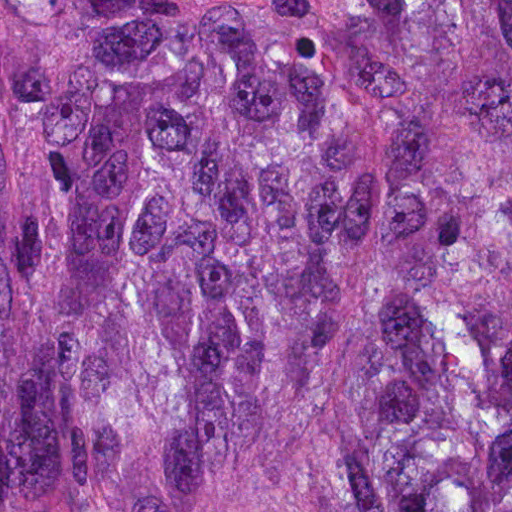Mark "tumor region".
<instances>
[{
    "label": "tumor region",
    "mask_w": 512,
    "mask_h": 512,
    "mask_svg": "<svg viewBox=\"0 0 512 512\" xmlns=\"http://www.w3.org/2000/svg\"><path fill=\"white\" fill-rule=\"evenodd\" d=\"M0 512H512V0H0Z\"/></svg>",
    "instance_id": "e687c5a6"
}]
</instances>
